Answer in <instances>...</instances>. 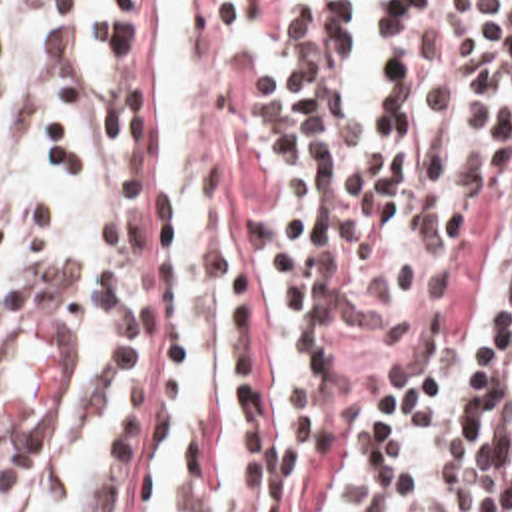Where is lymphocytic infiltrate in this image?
Masks as SVG:
<instances>
[{
    "label": "lymphocytic infiltrate",
    "instance_id": "lymphocytic-infiltrate-1",
    "mask_svg": "<svg viewBox=\"0 0 512 512\" xmlns=\"http://www.w3.org/2000/svg\"><path fill=\"white\" fill-rule=\"evenodd\" d=\"M360 38L254 56L202 92L192 170L224 405L180 443V512H512V0L384 12L376 128L346 86ZM98 44L108 88L80 42L43 36L51 168L64 180L92 136L100 264L62 262L39 212L0 344L51 312L90 358L78 429L108 381L130 389L60 512H146L182 375L172 208L158 92L120 84V0ZM60 457L0 453V497L64 489Z\"/></svg>",
    "mask_w": 512,
    "mask_h": 512
}]
</instances>
